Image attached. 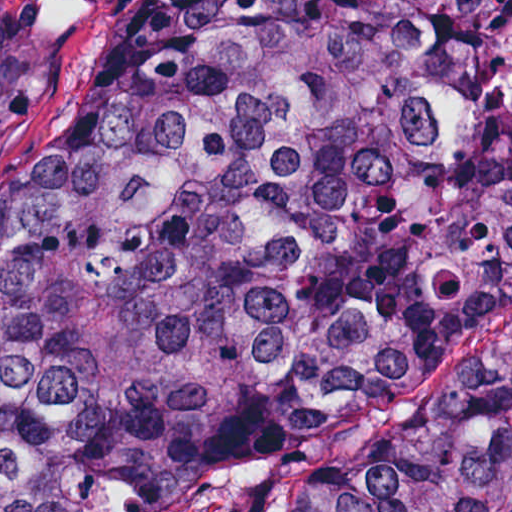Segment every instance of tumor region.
Returning a JSON list of instances; mask_svg holds the SVG:
<instances>
[{
    "label": "tumor region",
    "instance_id": "e687c5a6",
    "mask_svg": "<svg viewBox=\"0 0 512 512\" xmlns=\"http://www.w3.org/2000/svg\"><path fill=\"white\" fill-rule=\"evenodd\" d=\"M512 300V0H130L0 169V512H175ZM271 512H512V339Z\"/></svg>",
    "mask_w": 512,
    "mask_h": 512
}]
</instances>
